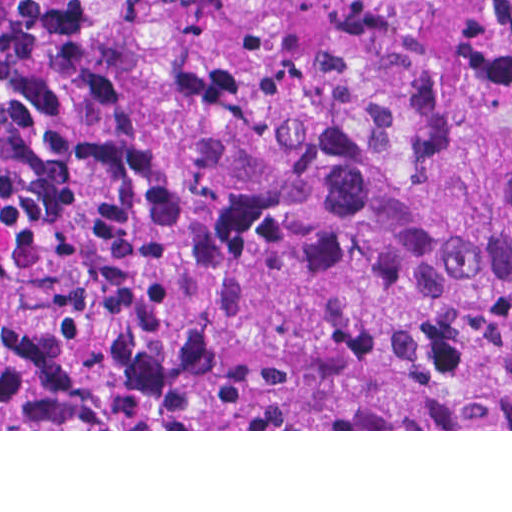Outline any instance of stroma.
I'll list each match as a JSON object with an SVG mask.
<instances>
[{"label": "stroma", "mask_w": 512, "mask_h": 512, "mask_svg": "<svg viewBox=\"0 0 512 512\" xmlns=\"http://www.w3.org/2000/svg\"><path fill=\"white\" fill-rule=\"evenodd\" d=\"M0 395L12 426V429H0V431H512V429L56 430L1 372Z\"/></svg>", "instance_id": "obj_1"}]
</instances>
